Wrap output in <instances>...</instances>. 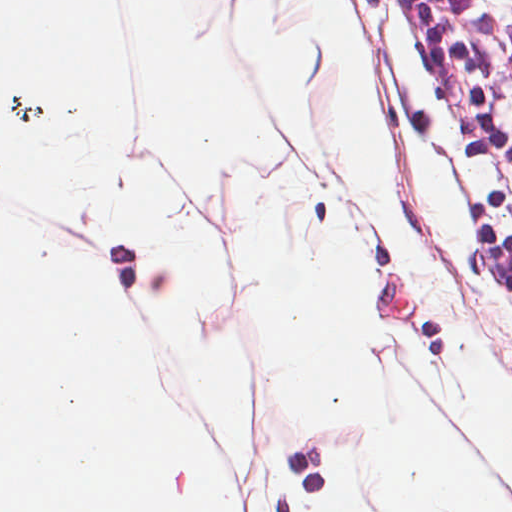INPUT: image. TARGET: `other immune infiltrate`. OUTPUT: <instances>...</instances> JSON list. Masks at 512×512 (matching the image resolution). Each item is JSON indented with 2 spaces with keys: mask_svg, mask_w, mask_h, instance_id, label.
I'll use <instances>...</instances> for the list:
<instances>
[{
  "mask_svg": "<svg viewBox=\"0 0 512 512\" xmlns=\"http://www.w3.org/2000/svg\"><path fill=\"white\" fill-rule=\"evenodd\" d=\"M432 42L512 205V75L463 0H424Z\"/></svg>",
  "mask_w": 512,
  "mask_h": 512,
  "instance_id": "1",
  "label": "other immune infiltrate"
}]
</instances>
